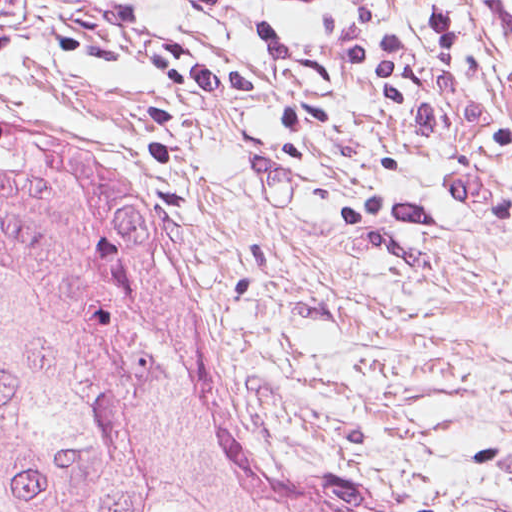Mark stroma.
I'll return each mask as SVG.
<instances>
[{
    "instance_id": "stroma-1",
    "label": "stroma",
    "mask_w": 512,
    "mask_h": 512,
    "mask_svg": "<svg viewBox=\"0 0 512 512\" xmlns=\"http://www.w3.org/2000/svg\"><path fill=\"white\" fill-rule=\"evenodd\" d=\"M159 283L230 395L366 512H512V355Z\"/></svg>"
}]
</instances>
